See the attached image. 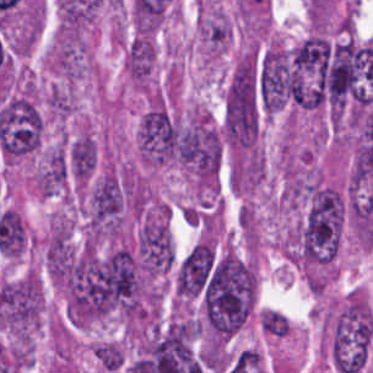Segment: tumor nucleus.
Masks as SVG:
<instances>
[{"mask_svg":"<svg viewBox=\"0 0 373 373\" xmlns=\"http://www.w3.org/2000/svg\"><path fill=\"white\" fill-rule=\"evenodd\" d=\"M178 151L183 169L198 192H217L222 166V137L218 125L202 110L177 124Z\"/></svg>","mask_w":373,"mask_h":373,"instance_id":"2f306a5c","label":"tumor nucleus"},{"mask_svg":"<svg viewBox=\"0 0 373 373\" xmlns=\"http://www.w3.org/2000/svg\"><path fill=\"white\" fill-rule=\"evenodd\" d=\"M97 161L93 137L81 132L66 146V172L77 181H87Z\"/></svg>","mask_w":373,"mask_h":373,"instance_id":"2cbd58db","label":"tumor nucleus"},{"mask_svg":"<svg viewBox=\"0 0 373 373\" xmlns=\"http://www.w3.org/2000/svg\"><path fill=\"white\" fill-rule=\"evenodd\" d=\"M125 203L124 181L109 171L100 176L88 191L86 231L120 233L124 223Z\"/></svg>","mask_w":373,"mask_h":373,"instance_id":"5ab6c2c4","label":"tumor nucleus"},{"mask_svg":"<svg viewBox=\"0 0 373 373\" xmlns=\"http://www.w3.org/2000/svg\"><path fill=\"white\" fill-rule=\"evenodd\" d=\"M138 150L147 165L182 163L183 151L176 122L164 104L150 101L142 113Z\"/></svg>","mask_w":373,"mask_h":373,"instance_id":"8643909e","label":"tumor nucleus"}]
</instances>
